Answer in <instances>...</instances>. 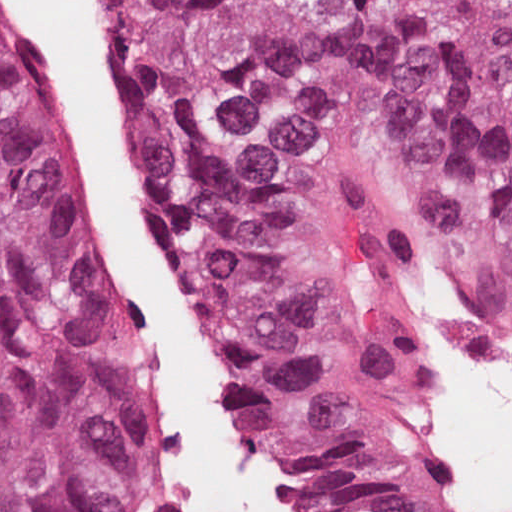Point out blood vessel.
Segmentation results:
<instances>
[{
  "mask_svg": "<svg viewBox=\"0 0 512 512\" xmlns=\"http://www.w3.org/2000/svg\"><path fill=\"white\" fill-rule=\"evenodd\" d=\"M409 357L415 390V409L433 439L448 475L465 500L461 494L450 455L442 439V393L435 373L434 306L429 307L414 333ZM149 512H178L172 471L163 447L160 451Z\"/></svg>",
  "mask_w": 512,
  "mask_h": 512,
  "instance_id": "blood-vessel-1",
  "label": "blood vessel"
}]
</instances>
